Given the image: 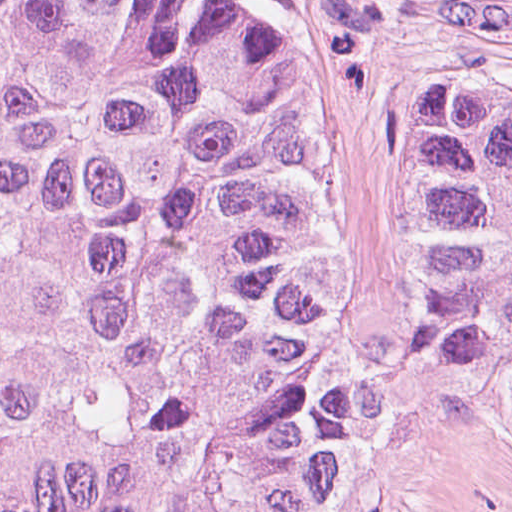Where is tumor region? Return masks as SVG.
<instances>
[{
  "instance_id": "tumor-region-1",
  "label": "tumor region",
  "mask_w": 512,
  "mask_h": 512,
  "mask_svg": "<svg viewBox=\"0 0 512 512\" xmlns=\"http://www.w3.org/2000/svg\"><path fill=\"white\" fill-rule=\"evenodd\" d=\"M411 287L512 433V96L393 97ZM321 58L221 0H0V512H341L379 458L321 260Z\"/></svg>"
}]
</instances>
